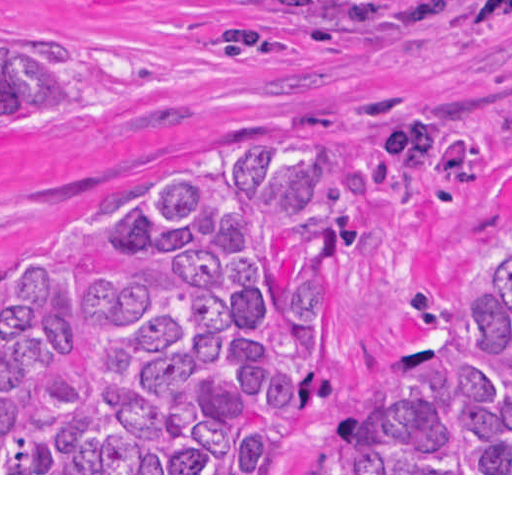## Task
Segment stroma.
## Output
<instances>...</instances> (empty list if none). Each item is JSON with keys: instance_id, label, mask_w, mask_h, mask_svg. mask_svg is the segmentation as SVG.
Listing matches in <instances>:
<instances>
[{"instance_id": "obj_1", "label": "stroma", "mask_w": 512, "mask_h": 512, "mask_svg": "<svg viewBox=\"0 0 512 512\" xmlns=\"http://www.w3.org/2000/svg\"><path fill=\"white\" fill-rule=\"evenodd\" d=\"M471 0H0V70L149 73L138 89L0 115V282L49 267L82 215L186 174L234 140L293 164L310 150L382 166L379 124L418 111L458 132L484 175L470 224L355 202L382 244L337 275L317 365L322 402L277 473H339L329 426L419 380L427 339L467 332L488 275L512 263V20L459 23Z\"/></svg>"}]
</instances>
